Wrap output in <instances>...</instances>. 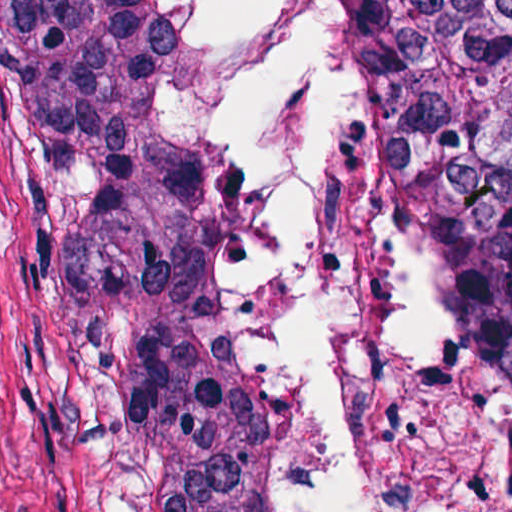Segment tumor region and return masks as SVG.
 <instances>
[{
	"label": "tumor region",
	"mask_w": 512,
	"mask_h": 512,
	"mask_svg": "<svg viewBox=\"0 0 512 512\" xmlns=\"http://www.w3.org/2000/svg\"><path fill=\"white\" fill-rule=\"evenodd\" d=\"M385 164L512 382V1H343ZM159 52L112 59V252L169 512H266L263 394L216 277L220 152L153 124Z\"/></svg>",
	"instance_id": "e687c5a6"
}]
</instances>
